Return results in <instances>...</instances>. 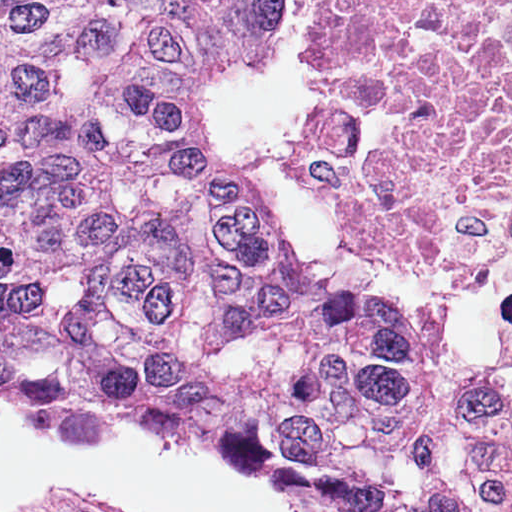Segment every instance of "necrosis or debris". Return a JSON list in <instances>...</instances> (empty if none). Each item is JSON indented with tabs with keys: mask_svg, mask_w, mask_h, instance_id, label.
Returning <instances> with one entry per match:
<instances>
[{
	"mask_svg": "<svg viewBox=\"0 0 512 512\" xmlns=\"http://www.w3.org/2000/svg\"><path fill=\"white\" fill-rule=\"evenodd\" d=\"M327 212L402 262L512 288V0H317Z\"/></svg>",
	"mask_w": 512,
	"mask_h": 512,
	"instance_id": "necrosis-or-debris-1",
	"label": "necrosis or debris"
}]
</instances>
